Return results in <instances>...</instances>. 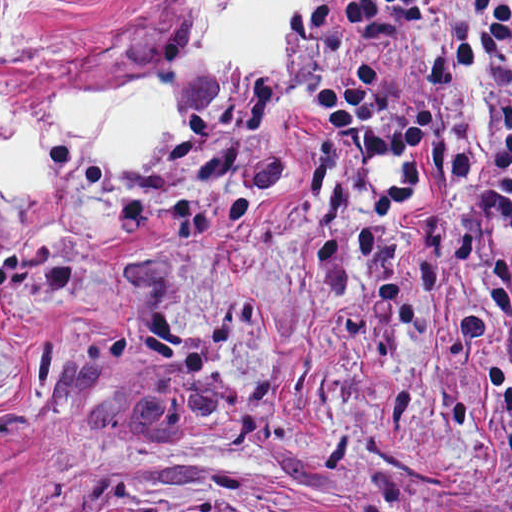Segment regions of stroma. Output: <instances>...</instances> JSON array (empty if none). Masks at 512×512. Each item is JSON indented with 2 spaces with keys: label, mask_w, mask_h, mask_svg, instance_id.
Here are the masks:
<instances>
[{
  "label": "stroma",
  "mask_w": 512,
  "mask_h": 512,
  "mask_svg": "<svg viewBox=\"0 0 512 512\" xmlns=\"http://www.w3.org/2000/svg\"><path fill=\"white\" fill-rule=\"evenodd\" d=\"M301 4L284 72L191 52L189 0H32L0 135L67 90L162 74L189 117L122 171L58 145L0 190V512H512V221L447 209L439 155L337 158L320 92L414 55ZM8 0H0V21Z\"/></svg>",
  "instance_id": "35a3bbf8"
}]
</instances>
